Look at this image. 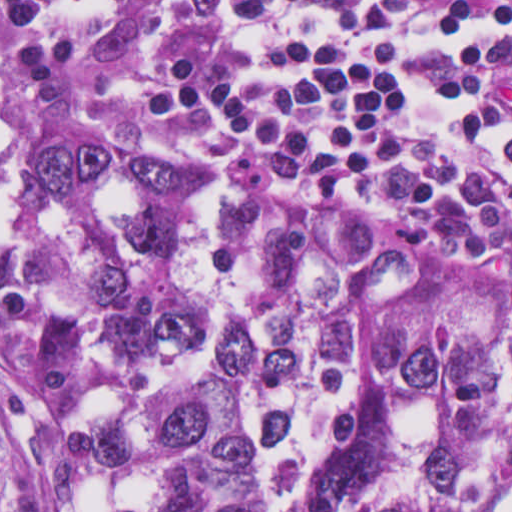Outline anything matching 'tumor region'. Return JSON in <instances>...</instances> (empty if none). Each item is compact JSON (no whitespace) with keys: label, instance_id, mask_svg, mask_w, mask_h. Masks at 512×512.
Here are the masks:
<instances>
[{"label":"tumor region","instance_id":"tumor-region-1","mask_svg":"<svg viewBox=\"0 0 512 512\" xmlns=\"http://www.w3.org/2000/svg\"><path fill=\"white\" fill-rule=\"evenodd\" d=\"M1 512H512V280L1 139Z\"/></svg>","mask_w":512,"mask_h":512}]
</instances>
